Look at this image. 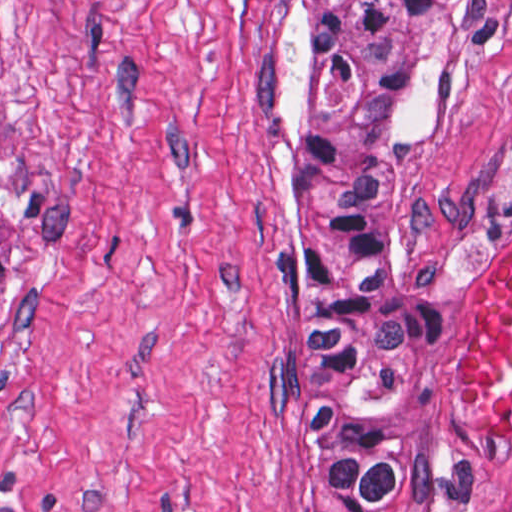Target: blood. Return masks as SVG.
Segmentation results:
<instances>
[{"instance_id":"obj_1","label":"blood","mask_w":512,"mask_h":512,"mask_svg":"<svg viewBox=\"0 0 512 512\" xmlns=\"http://www.w3.org/2000/svg\"><path fill=\"white\" fill-rule=\"evenodd\" d=\"M461 399L491 417H512V237L485 255L474 282Z\"/></svg>"}]
</instances>
